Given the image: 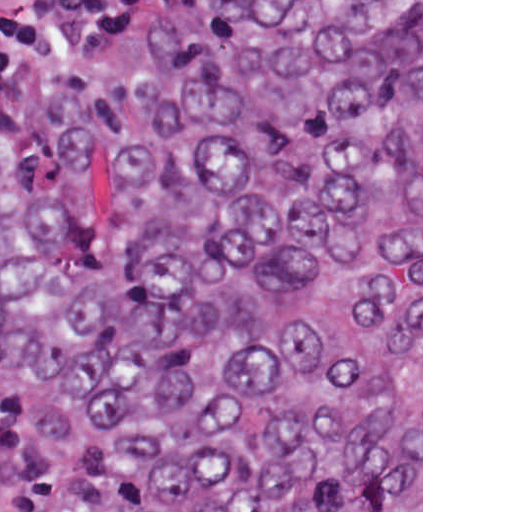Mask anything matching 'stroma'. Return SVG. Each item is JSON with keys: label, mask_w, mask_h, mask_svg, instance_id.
<instances>
[{"label": "stroma", "mask_w": 512, "mask_h": 512, "mask_svg": "<svg viewBox=\"0 0 512 512\" xmlns=\"http://www.w3.org/2000/svg\"><path fill=\"white\" fill-rule=\"evenodd\" d=\"M156 30L150 46L155 39ZM0 402L18 416L23 450L38 468L51 490V512H68V489L39 435L26 421L20 409L1 389ZM421 512H423V0H421Z\"/></svg>", "instance_id": "35a3bbf8"}]
</instances>
